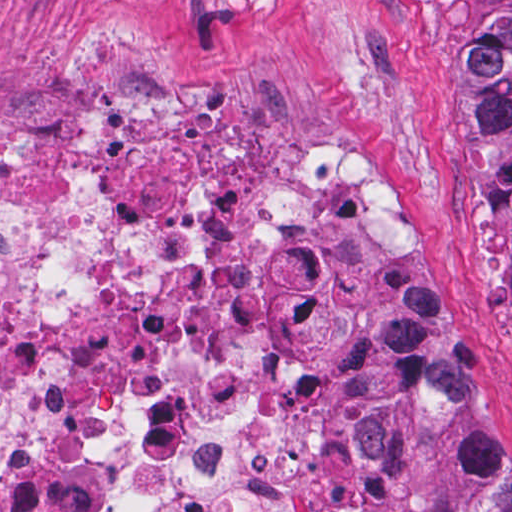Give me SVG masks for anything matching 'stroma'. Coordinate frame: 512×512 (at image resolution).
Returning a JSON list of instances; mask_svg holds the SVG:
<instances>
[{"label": "stroma", "mask_w": 512, "mask_h": 512, "mask_svg": "<svg viewBox=\"0 0 512 512\" xmlns=\"http://www.w3.org/2000/svg\"><path fill=\"white\" fill-rule=\"evenodd\" d=\"M464 66L456 0H0V146L74 140L113 95L156 87L199 99L278 169L366 163L420 223L427 278L385 293L373 400L403 412L385 343L414 310L512 441L509 250L454 115ZM36 206L0 189V217ZM373 297L272 348L261 406L279 474L364 467ZM420 503L445 512L425 472Z\"/></svg>", "instance_id": "1"}]
</instances>
